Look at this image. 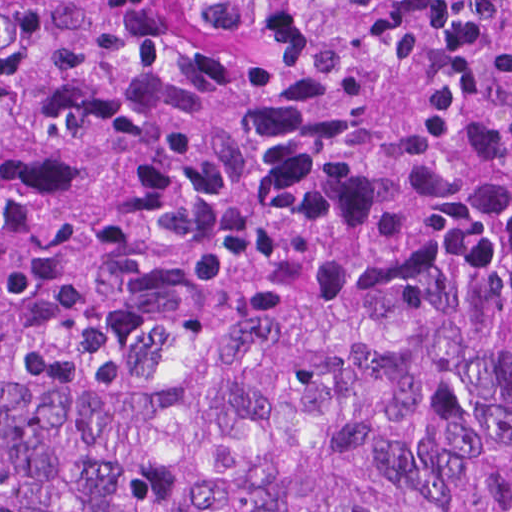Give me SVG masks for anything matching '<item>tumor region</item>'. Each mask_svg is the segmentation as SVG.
I'll return each instance as SVG.
<instances>
[{
	"label": "tumor region",
	"mask_w": 512,
	"mask_h": 512,
	"mask_svg": "<svg viewBox=\"0 0 512 512\" xmlns=\"http://www.w3.org/2000/svg\"><path fill=\"white\" fill-rule=\"evenodd\" d=\"M0 512H512V0H0Z\"/></svg>",
	"instance_id": "obj_1"
}]
</instances>
